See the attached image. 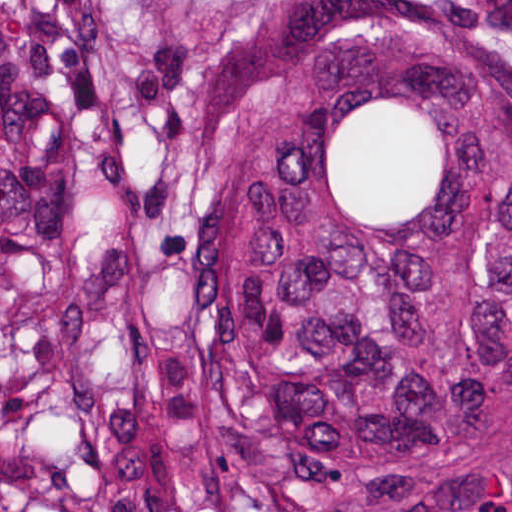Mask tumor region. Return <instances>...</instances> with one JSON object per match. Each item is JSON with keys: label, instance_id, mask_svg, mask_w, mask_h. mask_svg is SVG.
<instances>
[{"label": "tumor region", "instance_id": "obj_1", "mask_svg": "<svg viewBox=\"0 0 512 512\" xmlns=\"http://www.w3.org/2000/svg\"><path fill=\"white\" fill-rule=\"evenodd\" d=\"M0 512H512V1H0Z\"/></svg>", "mask_w": 512, "mask_h": 512}]
</instances>
